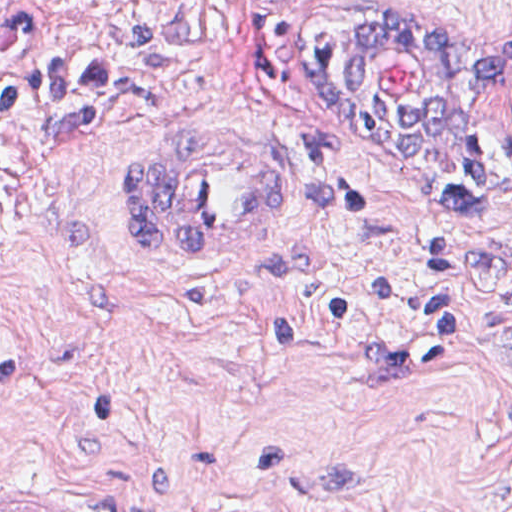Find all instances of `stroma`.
Instances as JSON below:
<instances>
[{
	"label": "stroma",
	"instance_id": "1",
	"mask_svg": "<svg viewBox=\"0 0 512 512\" xmlns=\"http://www.w3.org/2000/svg\"><path fill=\"white\" fill-rule=\"evenodd\" d=\"M402 6L445 34L512 23V0L307 28L234 0L40 2L47 50L126 80L20 112L0 156V504L512 512V231L457 207L444 158L381 148L323 71L340 18ZM508 130L512 91L468 137ZM195 143L287 185L257 252L128 240L122 169Z\"/></svg>",
	"mask_w": 512,
	"mask_h": 512
}]
</instances>
